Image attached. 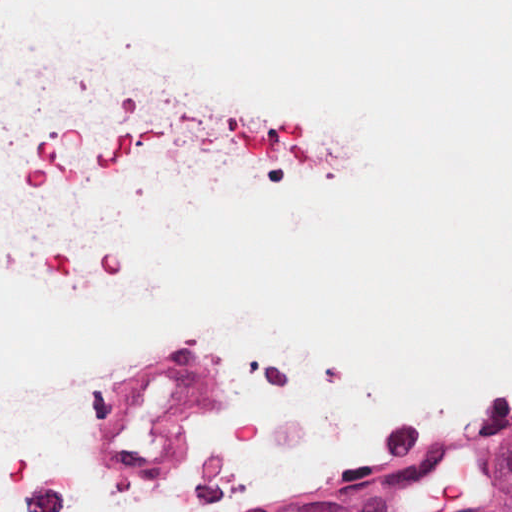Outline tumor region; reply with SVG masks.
I'll return each instance as SVG.
<instances>
[{"mask_svg": "<svg viewBox=\"0 0 512 512\" xmlns=\"http://www.w3.org/2000/svg\"><path fill=\"white\" fill-rule=\"evenodd\" d=\"M455 512H512V443L479 468L473 488Z\"/></svg>", "mask_w": 512, "mask_h": 512, "instance_id": "1", "label": "tumor region"}]
</instances>
